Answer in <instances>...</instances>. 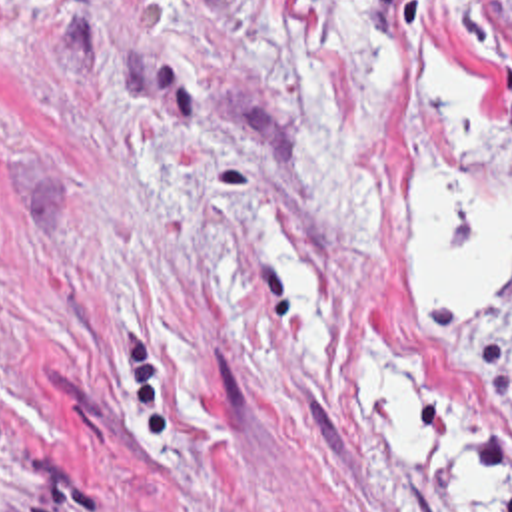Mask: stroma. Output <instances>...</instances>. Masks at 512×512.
Masks as SVG:
<instances>
[{
  "mask_svg": "<svg viewBox=\"0 0 512 512\" xmlns=\"http://www.w3.org/2000/svg\"><path fill=\"white\" fill-rule=\"evenodd\" d=\"M424 64L512 128V0H0V512H406L390 397L512 425V274L408 295Z\"/></svg>",
  "mask_w": 512,
  "mask_h": 512,
  "instance_id": "stroma-1",
  "label": "stroma"
}]
</instances>
